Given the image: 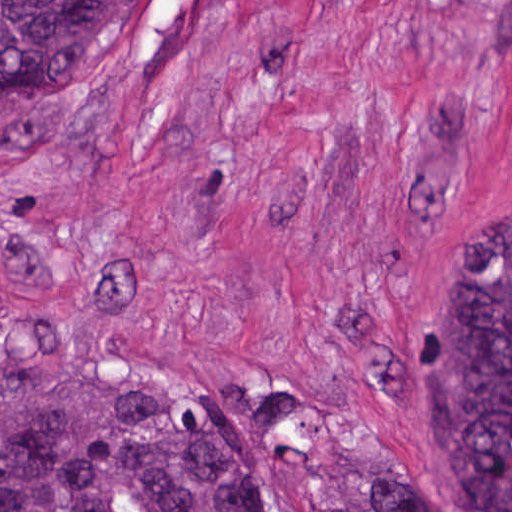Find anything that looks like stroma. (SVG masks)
I'll return each mask as SVG.
<instances>
[{
    "label": "stroma",
    "mask_w": 512,
    "mask_h": 512,
    "mask_svg": "<svg viewBox=\"0 0 512 512\" xmlns=\"http://www.w3.org/2000/svg\"><path fill=\"white\" fill-rule=\"evenodd\" d=\"M512 214V0H157L0 89V372L211 349L425 512L428 363ZM259 512H317L253 453Z\"/></svg>",
    "instance_id": "1"
}]
</instances>
